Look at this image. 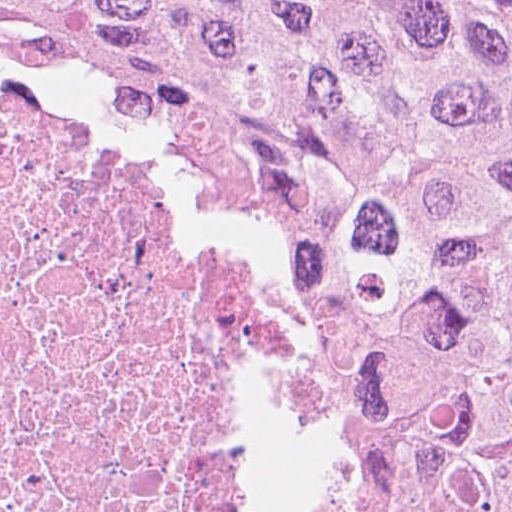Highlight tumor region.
Segmentation results:
<instances>
[{
	"mask_svg": "<svg viewBox=\"0 0 512 512\" xmlns=\"http://www.w3.org/2000/svg\"><path fill=\"white\" fill-rule=\"evenodd\" d=\"M222 165L407 512H512V0H0Z\"/></svg>",
	"mask_w": 512,
	"mask_h": 512,
	"instance_id": "e687c5a6",
	"label": "tumor region"
}]
</instances>
